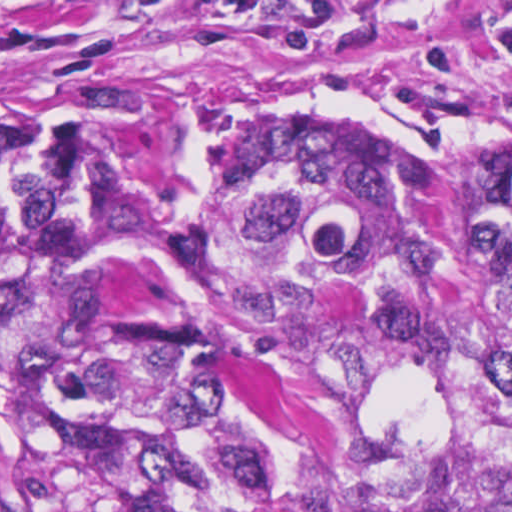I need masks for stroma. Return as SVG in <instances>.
Listing matches in <instances>:
<instances>
[{
    "label": "stroma",
    "mask_w": 512,
    "mask_h": 512,
    "mask_svg": "<svg viewBox=\"0 0 512 512\" xmlns=\"http://www.w3.org/2000/svg\"><path fill=\"white\" fill-rule=\"evenodd\" d=\"M1 126L135 203L259 134H356L425 175L512 192V0H0V512H42L1 396ZM213 279L228 365L213 434L300 452L296 386Z\"/></svg>",
    "instance_id": "35a3bbf8"
}]
</instances>
